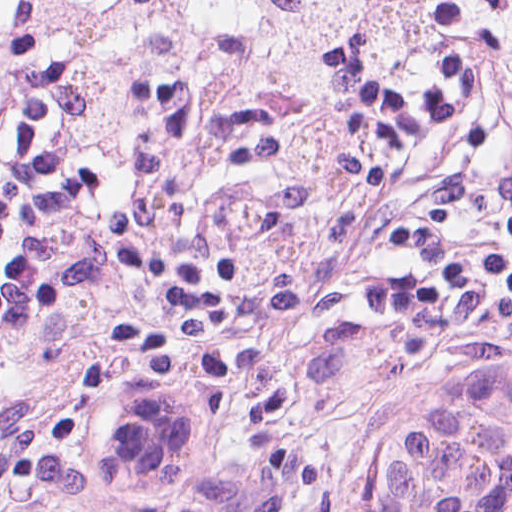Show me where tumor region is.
Listing matches in <instances>:
<instances>
[{"label": "tumor region", "instance_id": "1", "mask_svg": "<svg viewBox=\"0 0 512 512\" xmlns=\"http://www.w3.org/2000/svg\"><path fill=\"white\" fill-rule=\"evenodd\" d=\"M71 512H497L512 373L446 375L390 424L296 444L209 365H110L48 405Z\"/></svg>", "mask_w": 512, "mask_h": 512}]
</instances>
